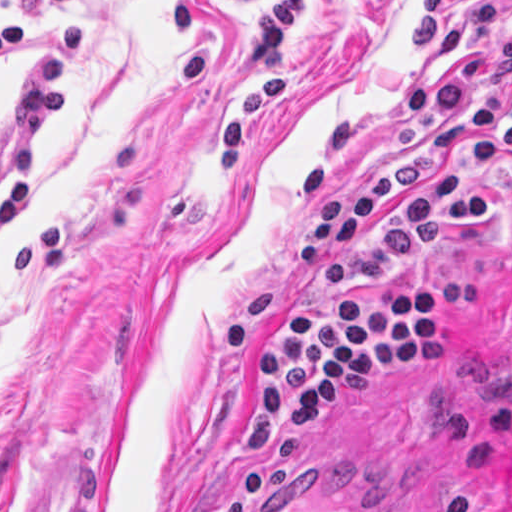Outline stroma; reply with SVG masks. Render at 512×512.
<instances>
[{
    "instance_id": "obj_1",
    "label": "stroma",
    "mask_w": 512,
    "mask_h": 512,
    "mask_svg": "<svg viewBox=\"0 0 512 512\" xmlns=\"http://www.w3.org/2000/svg\"><path fill=\"white\" fill-rule=\"evenodd\" d=\"M256 0H65L85 19L69 105L40 134L29 201L0 231V512H512V177L477 230H447L349 294H446V339L241 460L237 434L293 291L307 161L340 118L338 189L399 153V104L456 66L407 56L421 0H305L283 27L287 92L231 175L219 130L258 64ZM472 1L448 0L450 24ZM0 117L44 33L13 0ZM512 26V13L498 33ZM11 184L0 176V203Z\"/></svg>"
}]
</instances>
